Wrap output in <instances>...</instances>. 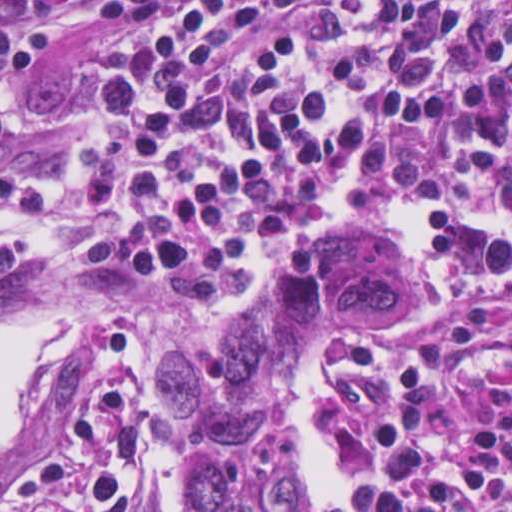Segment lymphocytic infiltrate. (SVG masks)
<instances>
[{
    "label": "lymphocytic infiltrate",
    "instance_id": "lymphocytic-infiltrate-1",
    "mask_svg": "<svg viewBox=\"0 0 512 512\" xmlns=\"http://www.w3.org/2000/svg\"><path fill=\"white\" fill-rule=\"evenodd\" d=\"M128 55L92 96L79 164L116 272L198 309L279 235L326 225L354 191L486 189L512 220V0H105ZM44 32L0 6V86L37 76ZM10 137L0 108V144ZM53 180L0 169V296L35 267L22 237ZM432 239L454 298L423 335L344 342L341 413L384 404L363 488L303 512H512V242L454 209ZM139 348L107 328L72 426L0 492V512H138Z\"/></svg>",
    "mask_w": 512,
    "mask_h": 512
}]
</instances>
